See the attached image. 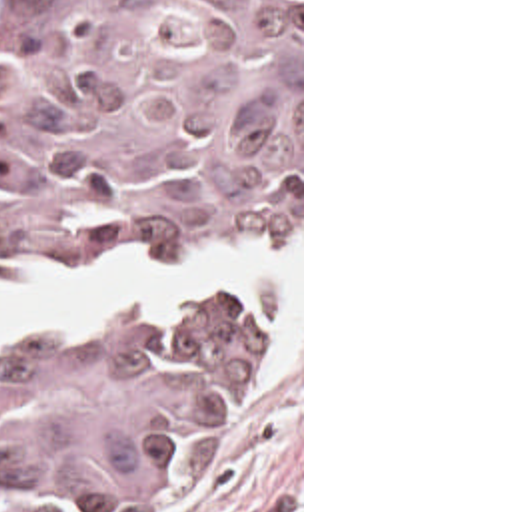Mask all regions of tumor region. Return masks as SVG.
I'll return each mask as SVG.
<instances>
[{
    "label": "tumor region",
    "mask_w": 512,
    "mask_h": 512,
    "mask_svg": "<svg viewBox=\"0 0 512 512\" xmlns=\"http://www.w3.org/2000/svg\"><path fill=\"white\" fill-rule=\"evenodd\" d=\"M298 209L300 0H6L0 269ZM266 323L260 291H212L142 337L0 345V512L180 490Z\"/></svg>",
    "instance_id": "obj_1"
}]
</instances>
